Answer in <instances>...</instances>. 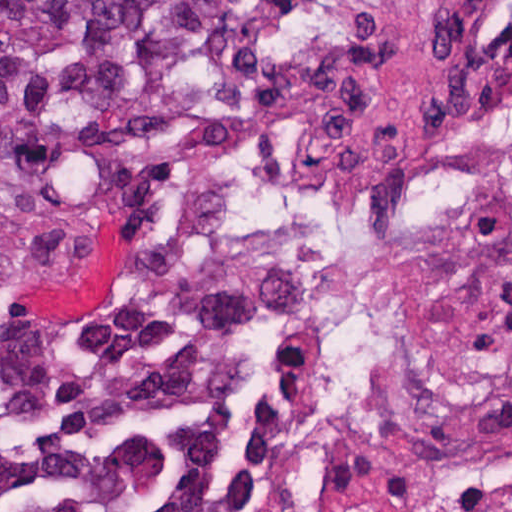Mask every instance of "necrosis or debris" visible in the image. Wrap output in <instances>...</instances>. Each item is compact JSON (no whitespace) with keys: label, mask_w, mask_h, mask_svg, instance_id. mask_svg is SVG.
Masks as SVG:
<instances>
[{"label":"necrosis or debris","mask_w":512,"mask_h":512,"mask_svg":"<svg viewBox=\"0 0 512 512\" xmlns=\"http://www.w3.org/2000/svg\"><path fill=\"white\" fill-rule=\"evenodd\" d=\"M242 212L295 362L298 512H512V0L486 2L400 138L257 163ZM98 247L0 230V353L10 304Z\"/></svg>","instance_id":"obj_1"}]
</instances>
